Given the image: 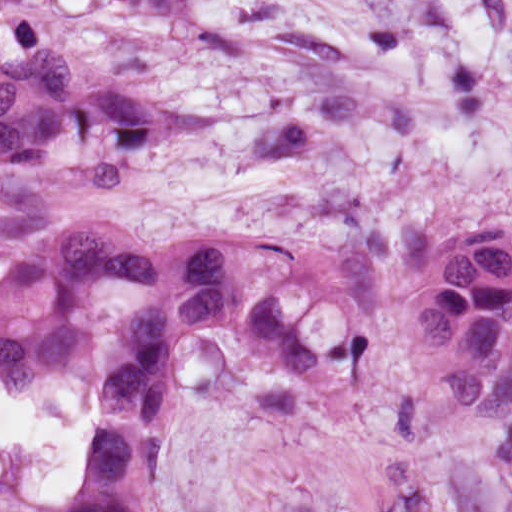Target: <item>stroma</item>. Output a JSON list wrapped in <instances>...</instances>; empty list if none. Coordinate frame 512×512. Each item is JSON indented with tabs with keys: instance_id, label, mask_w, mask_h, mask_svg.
<instances>
[{
	"instance_id": "1",
	"label": "stroma",
	"mask_w": 512,
	"mask_h": 512,
	"mask_svg": "<svg viewBox=\"0 0 512 512\" xmlns=\"http://www.w3.org/2000/svg\"><path fill=\"white\" fill-rule=\"evenodd\" d=\"M498 218H512V117L221 245L247 302L266 284L305 349L380 326L366 389L313 427H272L255 394L295 372L238 330H188L147 512H512V419L453 426L404 350L430 249ZM157 298L124 289L100 300L113 317L88 381L95 422L97 396L133 366L123 325ZM80 496L81 475L66 500L12 512H71Z\"/></svg>"
}]
</instances>
